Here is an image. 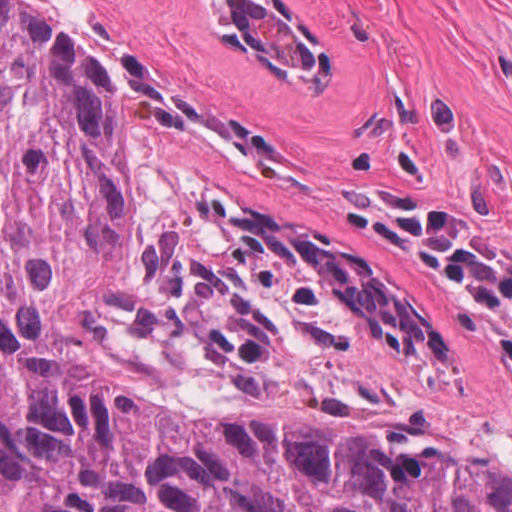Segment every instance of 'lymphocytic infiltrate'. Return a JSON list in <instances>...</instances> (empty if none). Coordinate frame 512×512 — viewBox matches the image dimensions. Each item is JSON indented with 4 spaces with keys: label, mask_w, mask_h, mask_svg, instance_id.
<instances>
[{
    "label": "lymphocytic infiltrate",
    "mask_w": 512,
    "mask_h": 512,
    "mask_svg": "<svg viewBox=\"0 0 512 512\" xmlns=\"http://www.w3.org/2000/svg\"><path fill=\"white\" fill-rule=\"evenodd\" d=\"M348 200L446 284L499 354L512 387V251L492 231L440 217L396 191L362 188Z\"/></svg>",
    "instance_id": "obj_1"
}]
</instances>
